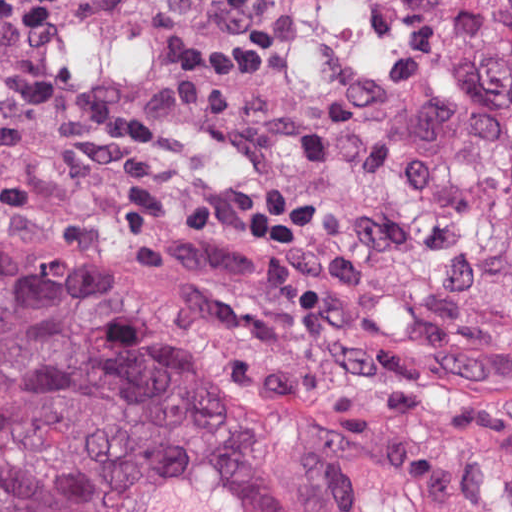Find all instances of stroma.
Here are the masks:
<instances>
[{"mask_svg":"<svg viewBox=\"0 0 512 512\" xmlns=\"http://www.w3.org/2000/svg\"><path fill=\"white\" fill-rule=\"evenodd\" d=\"M226 2L57 0L43 13L31 71L127 108L137 137L119 157L0 141V267L275 422L512 512V291L390 269L256 174Z\"/></svg>","mask_w":512,"mask_h":512,"instance_id":"obj_1","label":"stroma"}]
</instances>
